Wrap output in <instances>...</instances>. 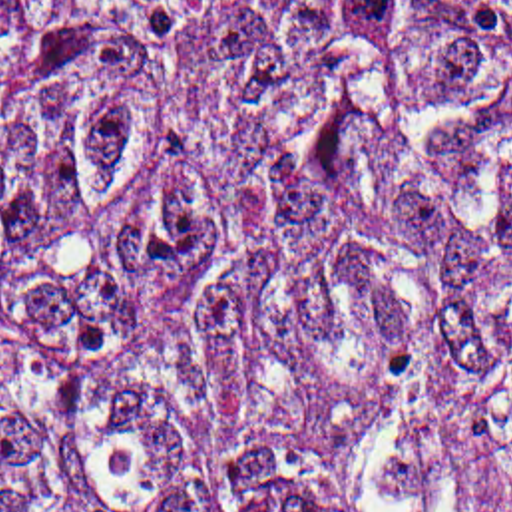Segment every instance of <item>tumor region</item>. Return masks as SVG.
I'll return each instance as SVG.
<instances>
[{"label":"tumor region","mask_w":512,"mask_h":512,"mask_svg":"<svg viewBox=\"0 0 512 512\" xmlns=\"http://www.w3.org/2000/svg\"><path fill=\"white\" fill-rule=\"evenodd\" d=\"M0 512H512V0H0Z\"/></svg>","instance_id":"1"}]
</instances>
